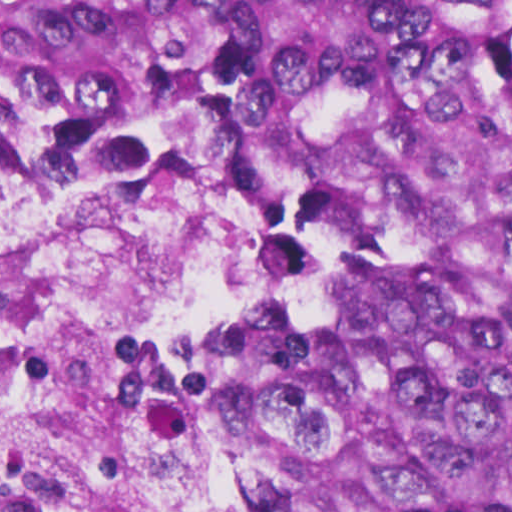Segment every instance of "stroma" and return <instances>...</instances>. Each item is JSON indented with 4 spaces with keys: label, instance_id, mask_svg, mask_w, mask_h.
I'll return each mask as SVG.
<instances>
[{
    "label": "stroma",
    "instance_id": "35a3bbf8",
    "mask_svg": "<svg viewBox=\"0 0 512 512\" xmlns=\"http://www.w3.org/2000/svg\"><path fill=\"white\" fill-rule=\"evenodd\" d=\"M29 171H66L88 180L104 198H185L202 184L229 188L238 204V294L231 310L176 358L168 379V431L183 512H232L194 433L189 404L200 380L268 319L283 268L268 240L289 190L278 161L234 136L205 131L151 182L111 183L86 173L75 147L49 142L0 157V228L11 188Z\"/></svg>",
    "mask_w": 512,
    "mask_h": 512
}]
</instances>
